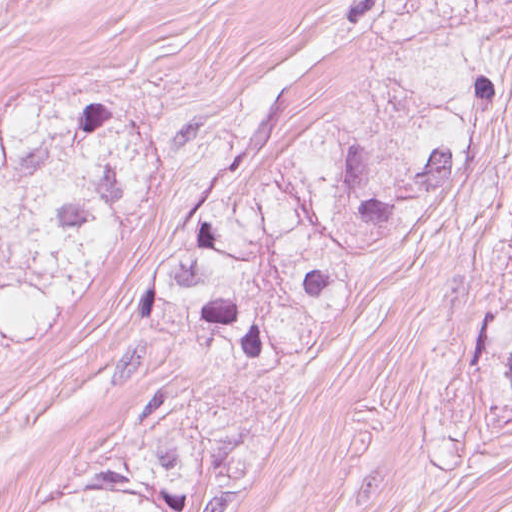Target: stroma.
Instances as JSON below:
<instances>
[{
  "label": "stroma",
  "instance_id": "35a3bbf8",
  "mask_svg": "<svg viewBox=\"0 0 512 512\" xmlns=\"http://www.w3.org/2000/svg\"><path fill=\"white\" fill-rule=\"evenodd\" d=\"M74 478L24 461L13 492L0 502V512H29L39 500Z\"/></svg>",
  "mask_w": 512,
  "mask_h": 512
}]
</instances>
